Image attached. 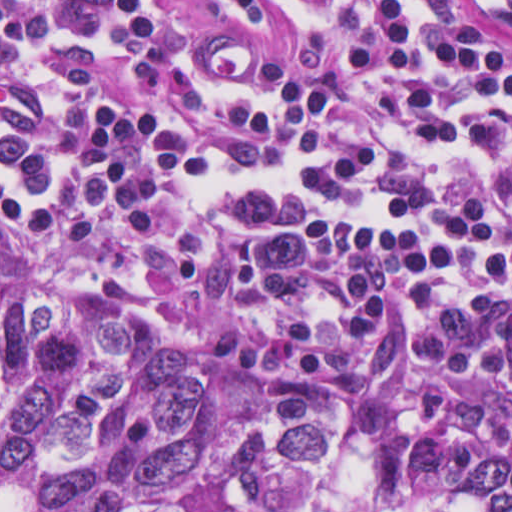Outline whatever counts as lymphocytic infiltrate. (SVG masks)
Listing matches in <instances>:
<instances>
[{
    "label": "lymphocytic infiltrate",
    "mask_w": 512,
    "mask_h": 512,
    "mask_svg": "<svg viewBox=\"0 0 512 512\" xmlns=\"http://www.w3.org/2000/svg\"><path fill=\"white\" fill-rule=\"evenodd\" d=\"M232 1L287 65L170 0H0V258L512 463V51L461 0Z\"/></svg>",
    "instance_id": "1"
}]
</instances>
